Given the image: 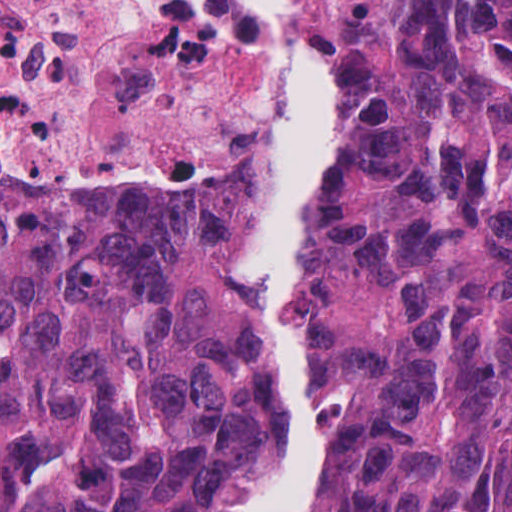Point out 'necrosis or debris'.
I'll use <instances>...</instances> for the list:
<instances>
[{
	"instance_id": "necrosis-or-debris-1",
	"label": "necrosis or debris",
	"mask_w": 512,
	"mask_h": 512,
	"mask_svg": "<svg viewBox=\"0 0 512 512\" xmlns=\"http://www.w3.org/2000/svg\"><path fill=\"white\" fill-rule=\"evenodd\" d=\"M278 105L238 0H0V185L225 184Z\"/></svg>"
}]
</instances>
